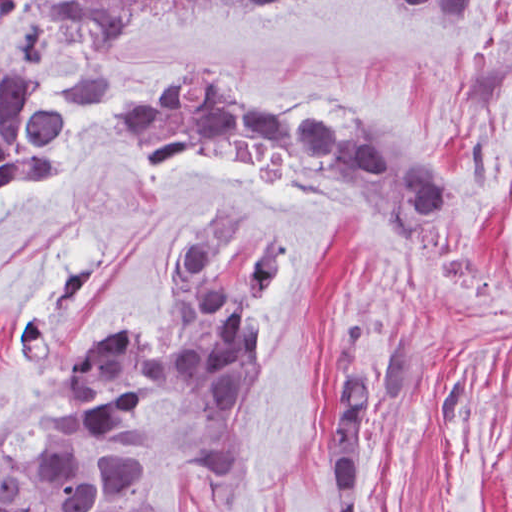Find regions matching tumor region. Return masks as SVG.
I'll return each mask as SVG.
<instances>
[{
  "label": "tumor region",
  "instance_id": "tumor-region-1",
  "mask_svg": "<svg viewBox=\"0 0 512 512\" xmlns=\"http://www.w3.org/2000/svg\"><path fill=\"white\" fill-rule=\"evenodd\" d=\"M161 1L222 10L294 0H71L66 13L86 32L87 50L67 100L43 101L26 56L0 60V198L59 178L70 157L72 108L109 105L117 27L135 8ZM393 1L442 21L474 22L475 0ZM110 124L145 165L201 145L254 165L281 187L355 208L403 251H419L430 229L459 222L457 195L407 145L326 97L262 112L212 64L185 62L149 89H131ZM289 270L288 244L248 203L200 207L164 264L159 333L138 316L117 320L114 334L64 370L33 422L0 442V512H164L169 494L140 417L149 401L169 398L233 427L269 370L271 307ZM359 327L356 312H344L328 350L325 468L337 512H360L372 409L382 399L400 403L417 386L413 332L396 330L357 368L350 356ZM246 464L235 443H217L195 459V479L227 494Z\"/></svg>",
  "mask_w": 512,
  "mask_h": 512
}]
</instances>
